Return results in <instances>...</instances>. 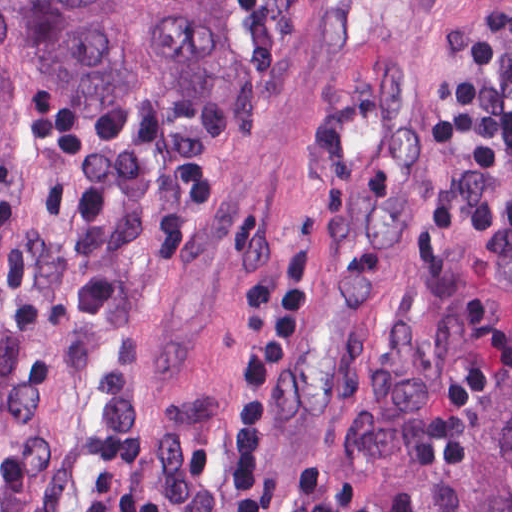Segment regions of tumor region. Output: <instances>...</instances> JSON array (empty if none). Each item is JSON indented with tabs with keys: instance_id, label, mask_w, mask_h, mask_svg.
<instances>
[{
	"instance_id": "tumor-region-1",
	"label": "tumor region",
	"mask_w": 512,
	"mask_h": 512,
	"mask_svg": "<svg viewBox=\"0 0 512 512\" xmlns=\"http://www.w3.org/2000/svg\"><path fill=\"white\" fill-rule=\"evenodd\" d=\"M237 0H0V512H50L67 437L136 424L154 196ZM437 512H512V382Z\"/></svg>"
}]
</instances>
